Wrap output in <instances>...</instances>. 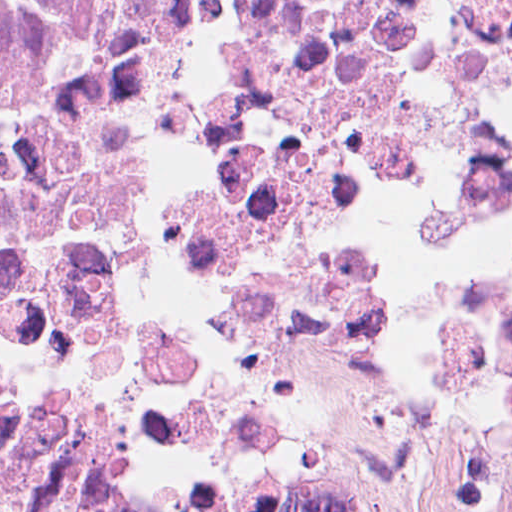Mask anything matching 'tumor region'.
I'll list each match as a JSON object with an SVG mask.
<instances>
[{
	"mask_svg": "<svg viewBox=\"0 0 512 512\" xmlns=\"http://www.w3.org/2000/svg\"><path fill=\"white\" fill-rule=\"evenodd\" d=\"M0 512H273L151 409H63L0 441Z\"/></svg>",
	"mask_w": 512,
	"mask_h": 512,
	"instance_id": "1",
	"label": "tumor region"
}]
</instances>
